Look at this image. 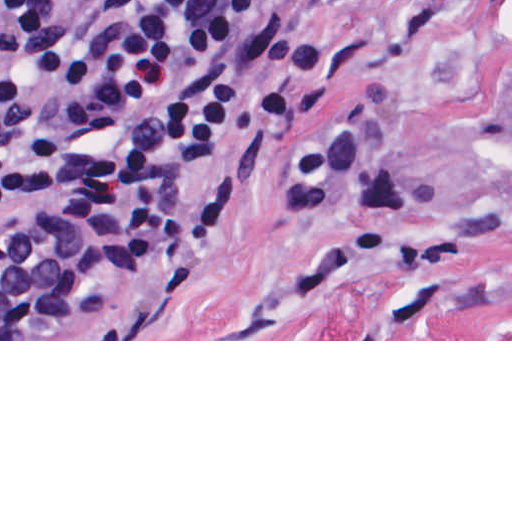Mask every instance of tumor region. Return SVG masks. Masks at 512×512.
<instances>
[{
	"instance_id": "tumor-region-1",
	"label": "tumor region",
	"mask_w": 512,
	"mask_h": 512,
	"mask_svg": "<svg viewBox=\"0 0 512 512\" xmlns=\"http://www.w3.org/2000/svg\"><path fill=\"white\" fill-rule=\"evenodd\" d=\"M478 111L498 137L512 146V6L488 41Z\"/></svg>"
}]
</instances>
